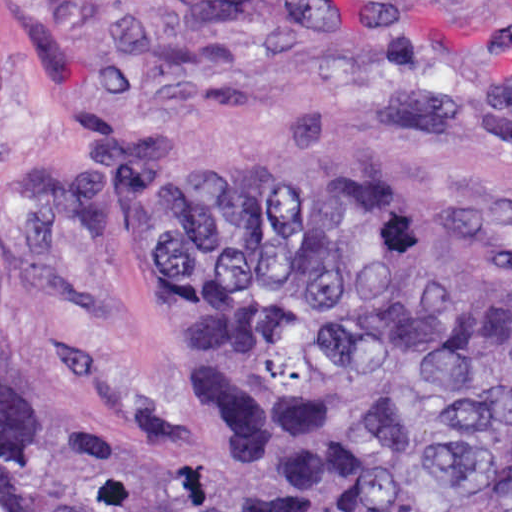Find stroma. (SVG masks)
Returning a JSON list of instances; mask_svg holds the SVG:
<instances>
[{"mask_svg":"<svg viewBox=\"0 0 512 512\" xmlns=\"http://www.w3.org/2000/svg\"><path fill=\"white\" fill-rule=\"evenodd\" d=\"M203 113L243 176L512 246V0H0V361L107 453L167 452L168 355L131 284L35 252L23 189Z\"/></svg>","mask_w":512,"mask_h":512,"instance_id":"obj_1","label":"stroma"}]
</instances>
